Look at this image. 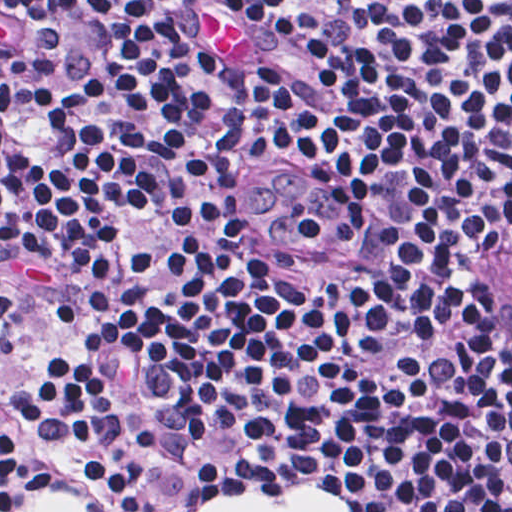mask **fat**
<instances>
[{"label": "fat", "mask_w": 512, "mask_h": 512, "mask_svg": "<svg viewBox=\"0 0 512 512\" xmlns=\"http://www.w3.org/2000/svg\"><path fill=\"white\" fill-rule=\"evenodd\" d=\"M227 6L229 12L213 5L206 11V47L224 59L256 61V44L250 30L228 3ZM39 512H91V509L75 497L49 495L40 498ZM197 512H350V507L315 487H294L276 497L216 494L204 500Z\"/></svg>", "instance_id": "obj_1"}]
</instances>
